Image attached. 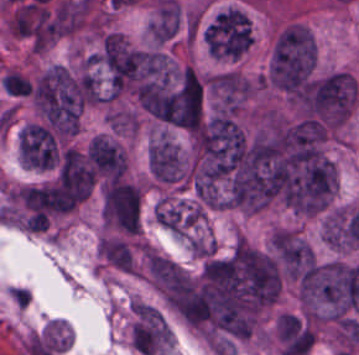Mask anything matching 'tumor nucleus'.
<instances>
[{
  "mask_svg": "<svg viewBox=\"0 0 359 355\" xmlns=\"http://www.w3.org/2000/svg\"><path fill=\"white\" fill-rule=\"evenodd\" d=\"M317 50L314 35L303 23H290L274 38L266 67V83L293 90L314 72Z\"/></svg>",
  "mask_w": 359,
  "mask_h": 355,
  "instance_id": "obj_1",
  "label": "tumor nucleus"
},
{
  "mask_svg": "<svg viewBox=\"0 0 359 355\" xmlns=\"http://www.w3.org/2000/svg\"><path fill=\"white\" fill-rule=\"evenodd\" d=\"M33 100L59 131H79L84 95L80 78L67 66L54 63L38 77Z\"/></svg>",
  "mask_w": 359,
  "mask_h": 355,
  "instance_id": "obj_2",
  "label": "tumor nucleus"
},
{
  "mask_svg": "<svg viewBox=\"0 0 359 355\" xmlns=\"http://www.w3.org/2000/svg\"><path fill=\"white\" fill-rule=\"evenodd\" d=\"M161 120L187 129L199 125L204 113V81L191 63H184L156 94Z\"/></svg>",
  "mask_w": 359,
  "mask_h": 355,
  "instance_id": "obj_3",
  "label": "tumor nucleus"
},
{
  "mask_svg": "<svg viewBox=\"0 0 359 355\" xmlns=\"http://www.w3.org/2000/svg\"><path fill=\"white\" fill-rule=\"evenodd\" d=\"M205 29L218 59L239 60L250 49L251 18L241 7H228Z\"/></svg>",
  "mask_w": 359,
  "mask_h": 355,
  "instance_id": "obj_4",
  "label": "tumor nucleus"
},
{
  "mask_svg": "<svg viewBox=\"0 0 359 355\" xmlns=\"http://www.w3.org/2000/svg\"><path fill=\"white\" fill-rule=\"evenodd\" d=\"M269 250L285 277L298 278L315 260L309 241L297 229L276 226L270 235Z\"/></svg>",
  "mask_w": 359,
  "mask_h": 355,
  "instance_id": "obj_5",
  "label": "tumor nucleus"
},
{
  "mask_svg": "<svg viewBox=\"0 0 359 355\" xmlns=\"http://www.w3.org/2000/svg\"><path fill=\"white\" fill-rule=\"evenodd\" d=\"M131 340L136 351L156 355L172 341V332L163 313L153 305H133Z\"/></svg>",
  "mask_w": 359,
  "mask_h": 355,
  "instance_id": "obj_6",
  "label": "tumor nucleus"
},
{
  "mask_svg": "<svg viewBox=\"0 0 359 355\" xmlns=\"http://www.w3.org/2000/svg\"><path fill=\"white\" fill-rule=\"evenodd\" d=\"M87 158L96 173L120 178L127 171V158L118 142L102 135H95L87 149Z\"/></svg>",
  "mask_w": 359,
  "mask_h": 355,
  "instance_id": "obj_7",
  "label": "tumor nucleus"
},
{
  "mask_svg": "<svg viewBox=\"0 0 359 355\" xmlns=\"http://www.w3.org/2000/svg\"><path fill=\"white\" fill-rule=\"evenodd\" d=\"M156 218L173 234H187L195 224V203L191 200L163 198L157 203Z\"/></svg>",
  "mask_w": 359,
  "mask_h": 355,
  "instance_id": "obj_8",
  "label": "tumor nucleus"
}]
</instances>
